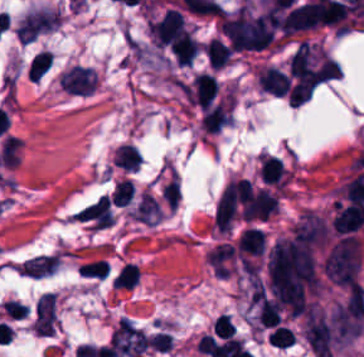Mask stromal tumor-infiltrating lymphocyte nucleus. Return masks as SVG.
<instances>
[{
    "label": "stromal tumor-infiltrating lymphocyte nucleus",
    "instance_id": "9",
    "mask_svg": "<svg viewBox=\"0 0 364 357\" xmlns=\"http://www.w3.org/2000/svg\"><path fill=\"white\" fill-rule=\"evenodd\" d=\"M205 51L211 64L218 69L228 63L234 52L231 45L220 36H213Z\"/></svg>",
    "mask_w": 364,
    "mask_h": 357
},
{
    "label": "stromal tumor-infiltrating lymphocyte nucleus",
    "instance_id": "1",
    "mask_svg": "<svg viewBox=\"0 0 364 357\" xmlns=\"http://www.w3.org/2000/svg\"><path fill=\"white\" fill-rule=\"evenodd\" d=\"M151 32L157 44H171L179 38L186 23L181 10L168 8L150 20Z\"/></svg>",
    "mask_w": 364,
    "mask_h": 357
},
{
    "label": "stromal tumor-infiltrating lymphocyte nucleus",
    "instance_id": "5",
    "mask_svg": "<svg viewBox=\"0 0 364 357\" xmlns=\"http://www.w3.org/2000/svg\"><path fill=\"white\" fill-rule=\"evenodd\" d=\"M233 117L234 100L231 98L206 106L201 115L203 125L211 132L229 123Z\"/></svg>",
    "mask_w": 364,
    "mask_h": 357
},
{
    "label": "stromal tumor-infiltrating lymphocyte nucleus",
    "instance_id": "10",
    "mask_svg": "<svg viewBox=\"0 0 364 357\" xmlns=\"http://www.w3.org/2000/svg\"><path fill=\"white\" fill-rule=\"evenodd\" d=\"M114 164L126 169L135 170L142 158L133 144L121 143L113 155Z\"/></svg>",
    "mask_w": 364,
    "mask_h": 357
},
{
    "label": "stromal tumor-infiltrating lymphocyte nucleus",
    "instance_id": "7",
    "mask_svg": "<svg viewBox=\"0 0 364 357\" xmlns=\"http://www.w3.org/2000/svg\"><path fill=\"white\" fill-rule=\"evenodd\" d=\"M199 43L190 30H184L173 42L170 50L177 65H191Z\"/></svg>",
    "mask_w": 364,
    "mask_h": 357
},
{
    "label": "stromal tumor-infiltrating lymphocyte nucleus",
    "instance_id": "2",
    "mask_svg": "<svg viewBox=\"0 0 364 357\" xmlns=\"http://www.w3.org/2000/svg\"><path fill=\"white\" fill-rule=\"evenodd\" d=\"M73 218L95 227H109L114 216L108 194H100L74 213Z\"/></svg>",
    "mask_w": 364,
    "mask_h": 357
},
{
    "label": "stromal tumor-infiltrating lymphocyte nucleus",
    "instance_id": "12",
    "mask_svg": "<svg viewBox=\"0 0 364 357\" xmlns=\"http://www.w3.org/2000/svg\"><path fill=\"white\" fill-rule=\"evenodd\" d=\"M133 194L134 188L131 180L129 178H122L112 194V199L117 205H125L132 199Z\"/></svg>",
    "mask_w": 364,
    "mask_h": 357
},
{
    "label": "stromal tumor-infiltrating lymphocyte nucleus",
    "instance_id": "6",
    "mask_svg": "<svg viewBox=\"0 0 364 357\" xmlns=\"http://www.w3.org/2000/svg\"><path fill=\"white\" fill-rule=\"evenodd\" d=\"M258 82L264 92L283 97L288 86L287 73L268 64L258 68Z\"/></svg>",
    "mask_w": 364,
    "mask_h": 357
},
{
    "label": "stromal tumor-infiltrating lymphocyte nucleus",
    "instance_id": "3",
    "mask_svg": "<svg viewBox=\"0 0 364 357\" xmlns=\"http://www.w3.org/2000/svg\"><path fill=\"white\" fill-rule=\"evenodd\" d=\"M364 222V207L356 203L336 202L333 226L336 232H350Z\"/></svg>",
    "mask_w": 364,
    "mask_h": 357
},
{
    "label": "stromal tumor-infiltrating lymphocyte nucleus",
    "instance_id": "8",
    "mask_svg": "<svg viewBox=\"0 0 364 357\" xmlns=\"http://www.w3.org/2000/svg\"><path fill=\"white\" fill-rule=\"evenodd\" d=\"M261 176L264 183L283 185L284 172L281 158L273 155H259Z\"/></svg>",
    "mask_w": 364,
    "mask_h": 357
},
{
    "label": "stromal tumor-infiltrating lymphocyte nucleus",
    "instance_id": "4",
    "mask_svg": "<svg viewBox=\"0 0 364 357\" xmlns=\"http://www.w3.org/2000/svg\"><path fill=\"white\" fill-rule=\"evenodd\" d=\"M218 89L219 85L215 74L198 72L194 77L190 101L202 109L213 100Z\"/></svg>",
    "mask_w": 364,
    "mask_h": 357
},
{
    "label": "stromal tumor-infiltrating lymphocyte nucleus",
    "instance_id": "11",
    "mask_svg": "<svg viewBox=\"0 0 364 357\" xmlns=\"http://www.w3.org/2000/svg\"><path fill=\"white\" fill-rule=\"evenodd\" d=\"M51 62L50 50L41 49L29 61L27 66V77L39 79L48 69Z\"/></svg>",
    "mask_w": 364,
    "mask_h": 357
}]
</instances>
